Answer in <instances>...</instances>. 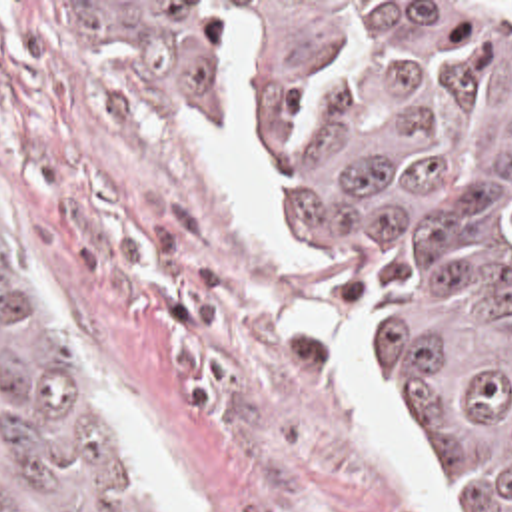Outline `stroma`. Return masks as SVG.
Returning <instances> with one entry per match:
<instances>
[{"instance_id":"35a3bbf8","label":"stroma","mask_w":512,"mask_h":512,"mask_svg":"<svg viewBox=\"0 0 512 512\" xmlns=\"http://www.w3.org/2000/svg\"><path fill=\"white\" fill-rule=\"evenodd\" d=\"M52 2H224L228 22H254L250 188L298 264L348 295L364 339V291L308 264L266 196L256 54L362 2L512 0H0V188L176 512H430L320 341L274 325V311L312 309L316 285L246 240L190 130L194 110H144L110 86L54 34ZM232 96L230 46L228 88L198 106L218 130ZM368 369L440 493L464 505Z\"/></svg>"}]
</instances>
